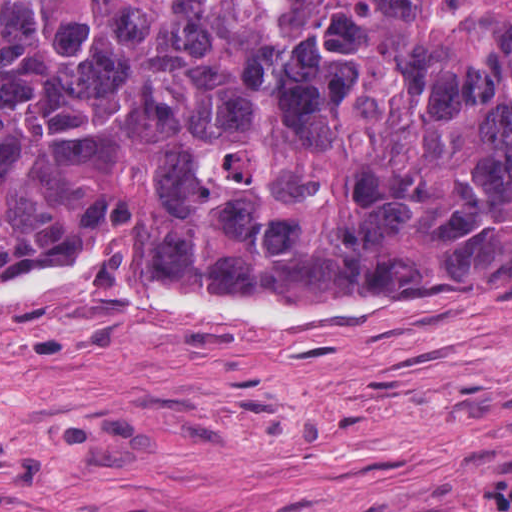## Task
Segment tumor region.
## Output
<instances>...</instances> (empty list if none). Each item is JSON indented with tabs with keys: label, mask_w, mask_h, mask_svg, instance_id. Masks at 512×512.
I'll use <instances>...</instances> for the list:
<instances>
[{
	"label": "tumor region",
	"mask_w": 512,
	"mask_h": 512,
	"mask_svg": "<svg viewBox=\"0 0 512 512\" xmlns=\"http://www.w3.org/2000/svg\"><path fill=\"white\" fill-rule=\"evenodd\" d=\"M512 300V0H0V277Z\"/></svg>",
	"instance_id": "e687c5a6"
}]
</instances>
